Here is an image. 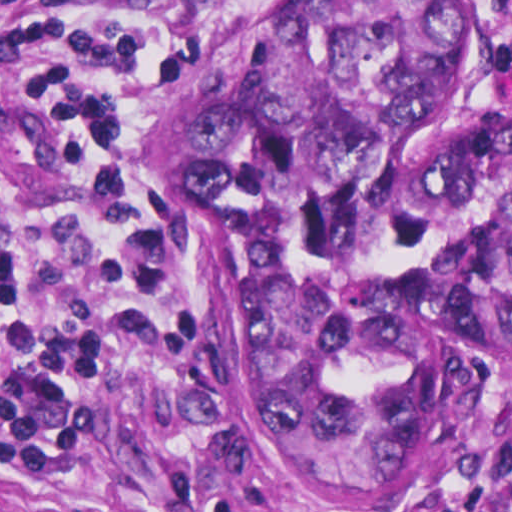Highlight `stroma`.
Instances as JSON below:
<instances>
[{"label": "stroma", "instance_id": "obj_1", "mask_svg": "<svg viewBox=\"0 0 512 512\" xmlns=\"http://www.w3.org/2000/svg\"><path fill=\"white\" fill-rule=\"evenodd\" d=\"M86 0H0V163L24 222H60L72 189L60 118L41 84L2 63L16 30ZM300 0H241L204 14L188 31L134 63L102 116L99 139L111 187L148 244L170 257L194 292V317L213 352L209 400L179 404L150 365L108 364L98 375L99 432L54 488L0 477V512H170L174 468H198L191 503L174 512H344L303 493L244 433L236 386V294L221 222L192 216L147 174L135 154L145 99L236 49ZM481 13L484 59L464 107L450 115H512L503 75L512 32L496 0ZM443 118L444 116H435ZM456 421L470 446L439 497L408 512H463L512 477V388L460 397Z\"/></svg>", "mask_w": 512, "mask_h": 512}]
</instances>
